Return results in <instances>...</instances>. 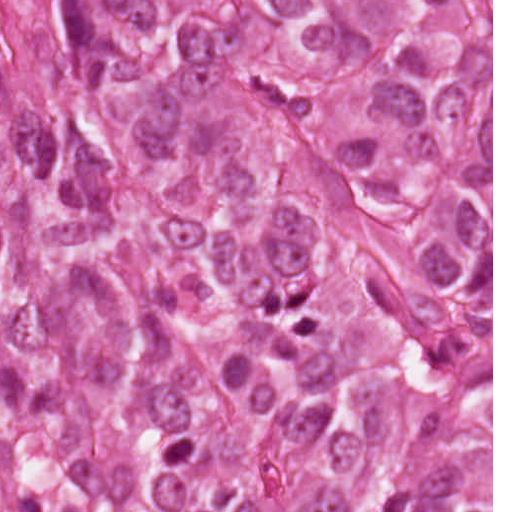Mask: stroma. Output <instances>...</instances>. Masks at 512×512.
Wrapping results in <instances>:
<instances>
[{"label":"stroma","mask_w":512,"mask_h":512,"mask_svg":"<svg viewBox=\"0 0 512 512\" xmlns=\"http://www.w3.org/2000/svg\"><path fill=\"white\" fill-rule=\"evenodd\" d=\"M491 365V512H493V0H492V344L485 342Z\"/></svg>","instance_id":"1"}]
</instances>
